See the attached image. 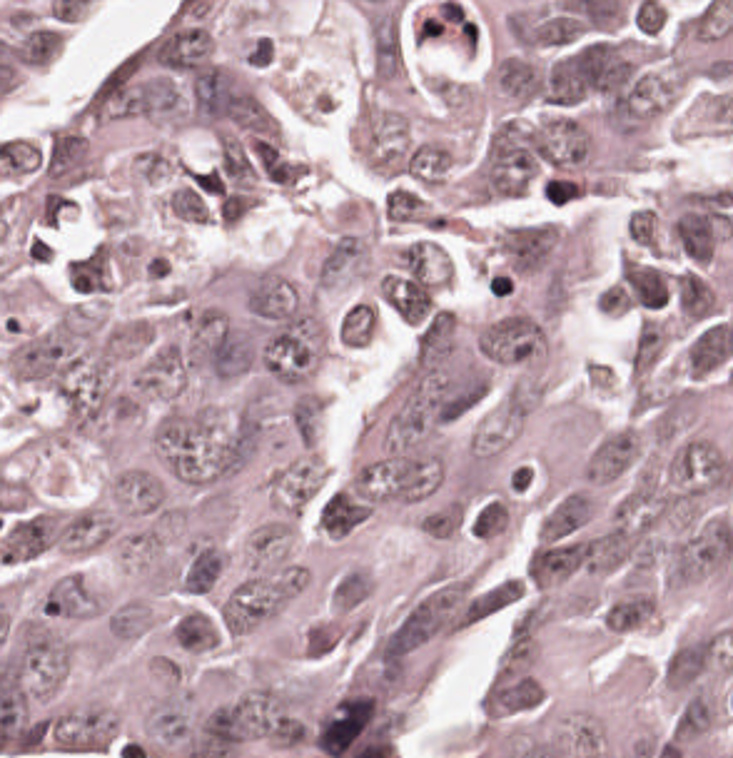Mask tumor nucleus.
I'll use <instances>...</instances> for the list:
<instances>
[{
    "mask_svg": "<svg viewBox=\"0 0 733 758\" xmlns=\"http://www.w3.org/2000/svg\"><path fill=\"white\" fill-rule=\"evenodd\" d=\"M260 440L245 401H171L154 408L144 432L153 473L174 494L215 499Z\"/></svg>",
    "mask_w": 733,
    "mask_h": 758,
    "instance_id": "2f306a5c",
    "label": "tumor nucleus"
},
{
    "mask_svg": "<svg viewBox=\"0 0 733 758\" xmlns=\"http://www.w3.org/2000/svg\"><path fill=\"white\" fill-rule=\"evenodd\" d=\"M732 644L720 625L677 639L661 680L676 719H721L730 706Z\"/></svg>",
    "mask_w": 733,
    "mask_h": 758,
    "instance_id": "8643909e",
    "label": "tumor nucleus"
},
{
    "mask_svg": "<svg viewBox=\"0 0 733 758\" xmlns=\"http://www.w3.org/2000/svg\"><path fill=\"white\" fill-rule=\"evenodd\" d=\"M542 680L527 658L506 655L487 674L478 690V716L514 719L532 709Z\"/></svg>",
    "mask_w": 733,
    "mask_h": 758,
    "instance_id": "5ab6c2c4",
    "label": "tumor nucleus"
},
{
    "mask_svg": "<svg viewBox=\"0 0 733 758\" xmlns=\"http://www.w3.org/2000/svg\"><path fill=\"white\" fill-rule=\"evenodd\" d=\"M543 342L540 317L511 308L478 331L473 347L491 362H522Z\"/></svg>",
    "mask_w": 733,
    "mask_h": 758,
    "instance_id": "2cbd58db",
    "label": "tumor nucleus"
},
{
    "mask_svg": "<svg viewBox=\"0 0 733 758\" xmlns=\"http://www.w3.org/2000/svg\"><path fill=\"white\" fill-rule=\"evenodd\" d=\"M366 248L367 229L346 216L315 257L311 282L325 290L362 277Z\"/></svg>",
    "mask_w": 733,
    "mask_h": 758,
    "instance_id": "3d1891a8",
    "label": "tumor nucleus"
},
{
    "mask_svg": "<svg viewBox=\"0 0 733 758\" xmlns=\"http://www.w3.org/2000/svg\"><path fill=\"white\" fill-rule=\"evenodd\" d=\"M493 245L508 272H554V221H528L501 229L493 236Z\"/></svg>",
    "mask_w": 733,
    "mask_h": 758,
    "instance_id": "2083b535",
    "label": "tumor nucleus"
}]
</instances>
